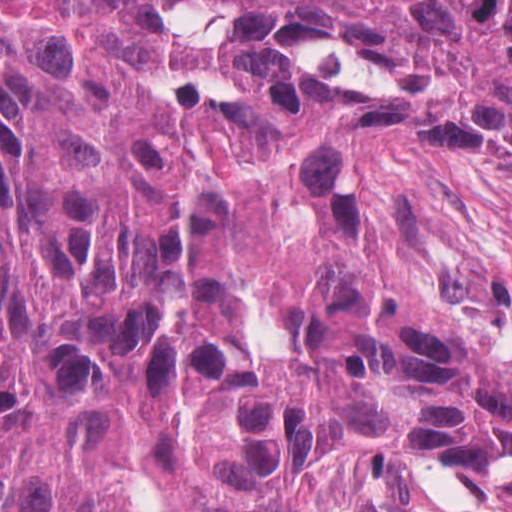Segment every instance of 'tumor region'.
Here are the masks:
<instances>
[{
  "label": "tumor region",
  "mask_w": 512,
  "mask_h": 512,
  "mask_svg": "<svg viewBox=\"0 0 512 512\" xmlns=\"http://www.w3.org/2000/svg\"><path fill=\"white\" fill-rule=\"evenodd\" d=\"M512 506V0H0V512Z\"/></svg>",
  "instance_id": "e687c5a6"
}]
</instances>
